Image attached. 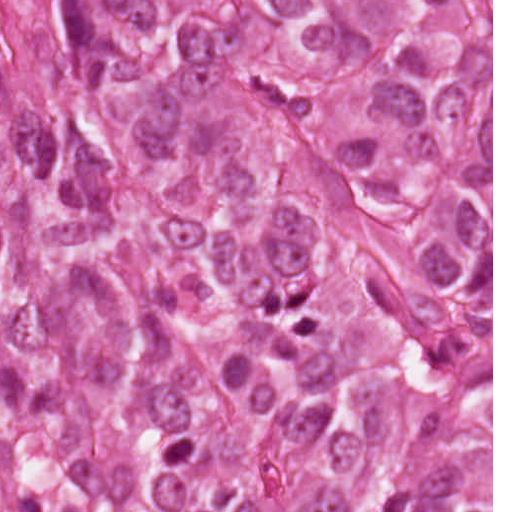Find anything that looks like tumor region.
<instances>
[{
  "instance_id": "obj_1",
  "label": "tumor region",
  "mask_w": 512,
  "mask_h": 512,
  "mask_svg": "<svg viewBox=\"0 0 512 512\" xmlns=\"http://www.w3.org/2000/svg\"><path fill=\"white\" fill-rule=\"evenodd\" d=\"M492 0H0V512H491Z\"/></svg>"
}]
</instances>
